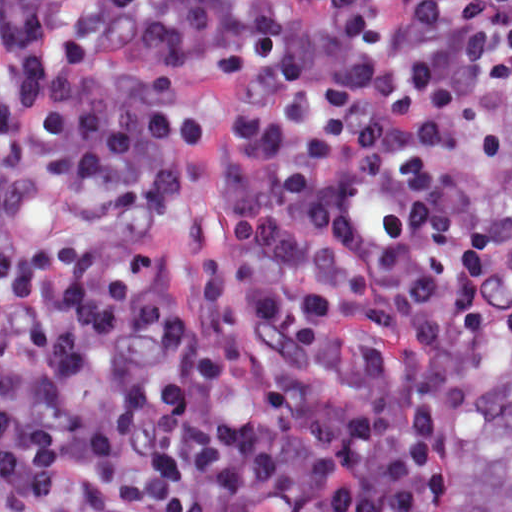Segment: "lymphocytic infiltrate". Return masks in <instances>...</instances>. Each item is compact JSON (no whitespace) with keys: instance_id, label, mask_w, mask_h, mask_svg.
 Segmentation results:
<instances>
[{"instance_id":"obj_1","label":"lymphocytic infiltrate","mask_w":512,"mask_h":512,"mask_svg":"<svg viewBox=\"0 0 512 512\" xmlns=\"http://www.w3.org/2000/svg\"><path fill=\"white\" fill-rule=\"evenodd\" d=\"M512 0H1V512H435ZM243 75L218 249L136 244Z\"/></svg>"}]
</instances>
